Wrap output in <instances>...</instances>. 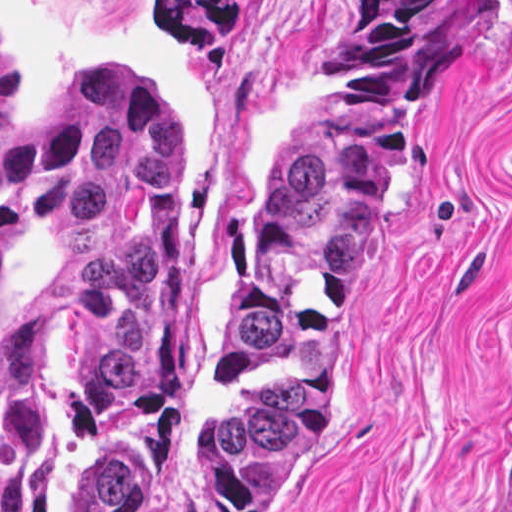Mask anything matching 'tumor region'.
Listing matches in <instances>:
<instances>
[{"instance_id": "tumor-region-1", "label": "tumor region", "mask_w": 512, "mask_h": 512, "mask_svg": "<svg viewBox=\"0 0 512 512\" xmlns=\"http://www.w3.org/2000/svg\"><path fill=\"white\" fill-rule=\"evenodd\" d=\"M466 2L346 1L218 330L225 512H281L319 446L368 240ZM166 11L184 46L239 22L233 0ZM44 405L64 426L66 512H171L200 407L195 215L178 118L143 63L79 66L36 122L17 119L0 65V512H28V412Z\"/></svg>"}]
</instances>
